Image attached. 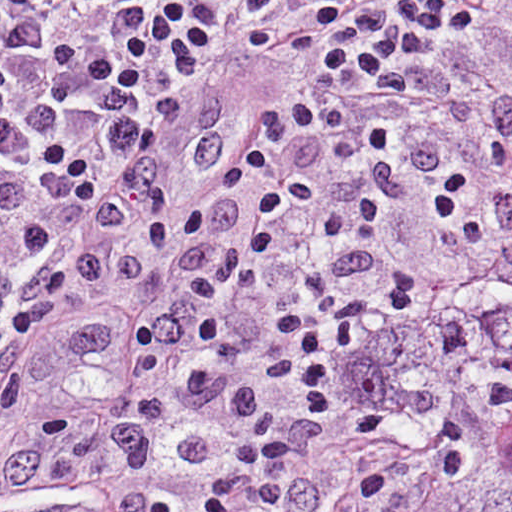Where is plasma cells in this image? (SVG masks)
<instances>
[{
    "label": "plasma cells",
    "mask_w": 512,
    "mask_h": 512,
    "mask_svg": "<svg viewBox=\"0 0 512 512\" xmlns=\"http://www.w3.org/2000/svg\"><path fill=\"white\" fill-rule=\"evenodd\" d=\"M477 0H0V320L39 333L72 380L159 361L276 270L405 112L438 38L468 50ZM308 59L303 99L174 229L164 174L189 116L195 166L227 139L191 77L227 28ZM476 53V52H475ZM322 403L247 405L215 447L207 512H257L302 487Z\"/></svg>",
    "instance_id": "9512152a"
}]
</instances>
